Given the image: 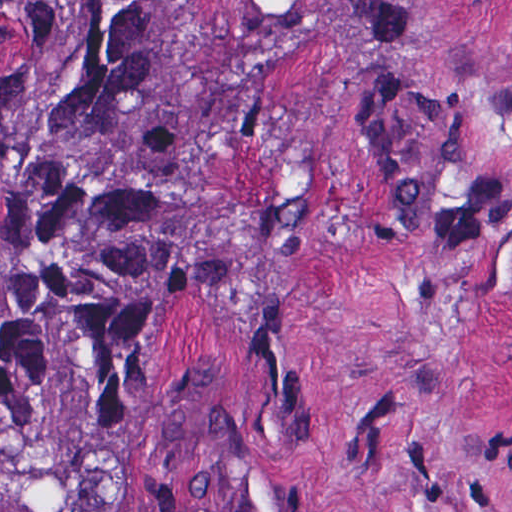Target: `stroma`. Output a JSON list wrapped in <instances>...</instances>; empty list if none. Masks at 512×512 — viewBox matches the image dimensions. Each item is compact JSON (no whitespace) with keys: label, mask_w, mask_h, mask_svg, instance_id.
I'll return each mask as SVG.
<instances>
[{"label":"stroma","mask_w":512,"mask_h":512,"mask_svg":"<svg viewBox=\"0 0 512 512\" xmlns=\"http://www.w3.org/2000/svg\"><path fill=\"white\" fill-rule=\"evenodd\" d=\"M214 240L123 373L127 512H512V0H193Z\"/></svg>","instance_id":"obj_1"}]
</instances>
